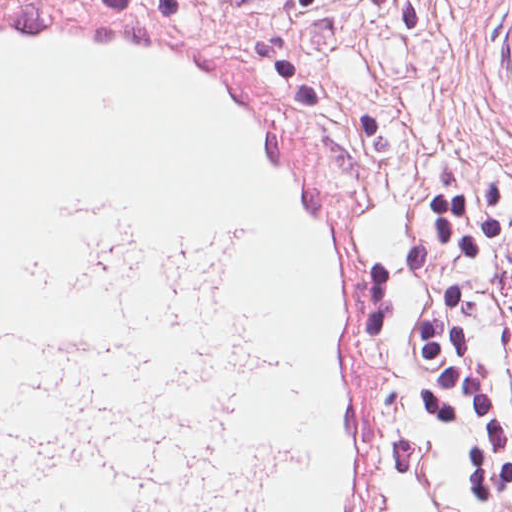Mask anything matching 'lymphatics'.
I'll return each mask as SVG.
<instances>
[{
  "label": "lymphatics",
  "mask_w": 512,
  "mask_h": 512,
  "mask_svg": "<svg viewBox=\"0 0 512 512\" xmlns=\"http://www.w3.org/2000/svg\"><path fill=\"white\" fill-rule=\"evenodd\" d=\"M53 305L0 303V512H270L305 411L240 233L76 192Z\"/></svg>",
  "instance_id": "lymphatics-1"
}]
</instances>
